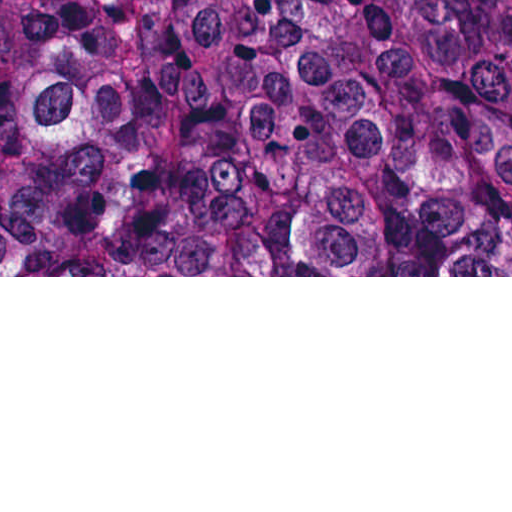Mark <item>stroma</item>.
Returning a JSON list of instances; mask_svg holds the SVG:
<instances>
[{
  "label": "stroma",
  "instance_id": "1",
  "mask_svg": "<svg viewBox=\"0 0 512 512\" xmlns=\"http://www.w3.org/2000/svg\"><path fill=\"white\" fill-rule=\"evenodd\" d=\"M0 277H512V268H0Z\"/></svg>",
  "mask_w": 512,
  "mask_h": 512
}]
</instances>
